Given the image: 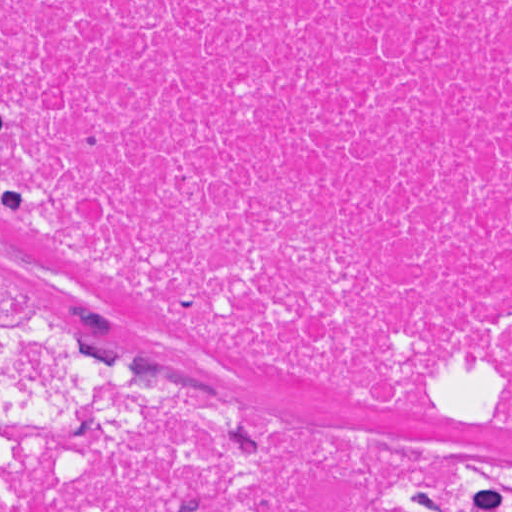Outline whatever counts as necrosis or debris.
<instances>
[{
	"label": "necrosis or debris",
	"instance_id": "necrosis-or-debris-1",
	"mask_svg": "<svg viewBox=\"0 0 512 512\" xmlns=\"http://www.w3.org/2000/svg\"><path fill=\"white\" fill-rule=\"evenodd\" d=\"M0 208L285 371L510 386L512 0H0ZM0 312V512H495L419 435L286 429Z\"/></svg>",
	"mask_w": 512,
	"mask_h": 512
}]
</instances>
